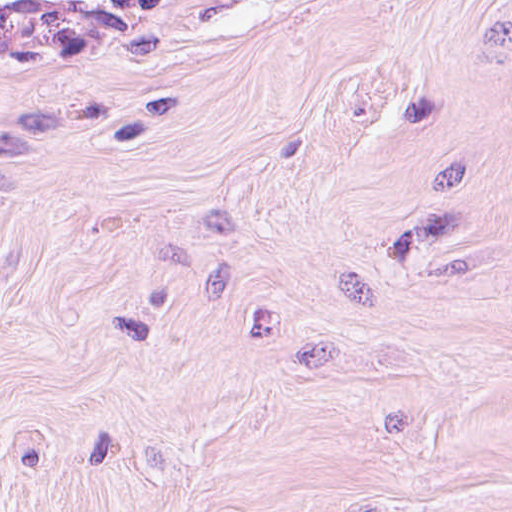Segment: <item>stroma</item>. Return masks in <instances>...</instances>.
Masks as SVG:
<instances>
[{"mask_svg":"<svg viewBox=\"0 0 512 512\" xmlns=\"http://www.w3.org/2000/svg\"><path fill=\"white\" fill-rule=\"evenodd\" d=\"M0 512H512V0H0Z\"/></svg>","mask_w":512,"mask_h":512,"instance_id":"stroma-1","label":"stroma"}]
</instances>
